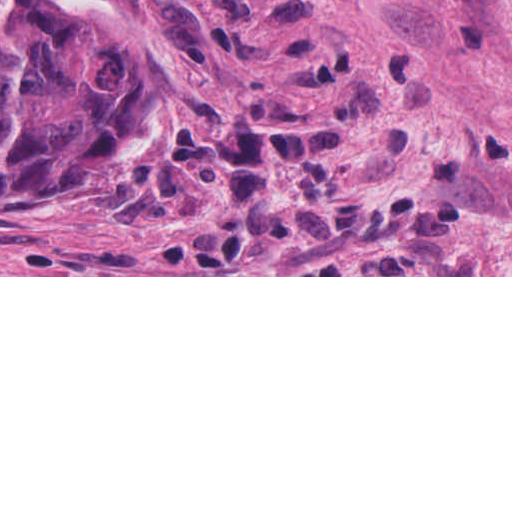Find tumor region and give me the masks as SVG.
Listing matches in <instances>:
<instances>
[{
    "instance_id": "1",
    "label": "tumor region",
    "mask_w": 512,
    "mask_h": 512,
    "mask_svg": "<svg viewBox=\"0 0 512 512\" xmlns=\"http://www.w3.org/2000/svg\"><path fill=\"white\" fill-rule=\"evenodd\" d=\"M189 119L99 0H0V202L155 175Z\"/></svg>"
}]
</instances>
